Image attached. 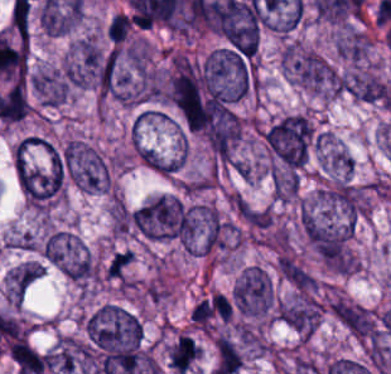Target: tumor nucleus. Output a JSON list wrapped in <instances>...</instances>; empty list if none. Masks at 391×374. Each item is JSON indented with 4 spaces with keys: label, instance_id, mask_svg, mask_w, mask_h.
Returning <instances> with one entry per match:
<instances>
[{
    "label": "tumor nucleus",
    "instance_id": "obj_1",
    "mask_svg": "<svg viewBox=\"0 0 391 374\" xmlns=\"http://www.w3.org/2000/svg\"><path fill=\"white\" fill-rule=\"evenodd\" d=\"M230 300L235 310L256 319H270L275 308V292L270 274L261 266L249 264L233 285Z\"/></svg>",
    "mask_w": 391,
    "mask_h": 374
},
{
    "label": "tumor nucleus",
    "instance_id": "obj_2",
    "mask_svg": "<svg viewBox=\"0 0 391 374\" xmlns=\"http://www.w3.org/2000/svg\"><path fill=\"white\" fill-rule=\"evenodd\" d=\"M42 258L72 281L84 282L92 276V263L85 246L62 231H54L40 244Z\"/></svg>",
    "mask_w": 391,
    "mask_h": 374
},
{
    "label": "tumor nucleus",
    "instance_id": "obj_3",
    "mask_svg": "<svg viewBox=\"0 0 391 374\" xmlns=\"http://www.w3.org/2000/svg\"><path fill=\"white\" fill-rule=\"evenodd\" d=\"M287 72L295 83L322 97L338 94L337 73L313 49L293 48L288 53Z\"/></svg>",
    "mask_w": 391,
    "mask_h": 374
},
{
    "label": "tumor nucleus",
    "instance_id": "obj_4",
    "mask_svg": "<svg viewBox=\"0 0 391 374\" xmlns=\"http://www.w3.org/2000/svg\"><path fill=\"white\" fill-rule=\"evenodd\" d=\"M63 161L71 182L86 191L107 187V167L102 155L84 141L72 139L63 146Z\"/></svg>",
    "mask_w": 391,
    "mask_h": 374
},
{
    "label": "tumor nucleus",
    "instance_id": "obj_5",
    "mask_svg": "<svg viewBox=\"0 0 391 374\" xmlns=\"http://www.w3.org/2000/svg\"><path fill=\"white\" fill-rule=\"evenodd\" d=\"M340 88L357 101L391 106V82L371 72L351 71L343 75Z\"/></svg>",
    "mask_w": 391,
    "mask_h": 374
},
{
    "label": "tumor nucleus",
    "instance_id": "obj_6",
    "mask_svg": "<svg viewBox=\"0 0 391 374\" xmlns=\"http://www.w3.org/2000/svg\"><path fill=\"white\" fill-rule=\"evenodd\" d=\"M279 318L300 337H308L319 320L315 299L303 298L279 304Z\"/></svg>",
    "mask_w": 391,
    "mask_h": 374
},
{
    "label": "tumor nucleus",
    "instance_id": "obj_7",
    "mask_svg": "<svg viewBox=\"0 0 391 374\" xmlns=\"http://www.w3.org/2000/svg\"><path fill=\"white\" fill-rule=\"evenodd\" d=\"M199 347L187 335H179L168 350L170 367L181 374H185L194 360Z\"/></svg>",
    "mask_w": 391,
    "mask_h": 374
},
{
    "label": "tumor nucleus",
    "instance_id": "obj_8",
    "mask_svg": "<svg viewBox=\"0 0 391 374\" xmlns=\"http://www.w3.org/2000/svg\"><path fill=\"white\" fill-rule=\"evenodd\" d=\"M335 46L338 55L357 62L365 55L368 40L361 32L348 28L338 35Z\"/></svg>",
    "mask_w": 391,
    "mask_h": 374
},
{
    "label": "tumor nucleus",
    "instance_id": "obj_9",
    "mask_svg": "<svg viewBox=\"0 0 391 374\" xmlns=\"http://www.w3.org/2000/svg\"><path fill=\"white\" fill-rule=\"evenodd\" d=\"M240 359L236 342L221 335L216 340L215 370L221 373H236Z\"/></svg>",
    "mask_w": 391,
    "mask_h": 374
},
{
    "label": "tumor nucleus",
    "instance_id": "obj_10",
    "mask_svg": "<svg viewBox=\"0 0 391 374\" xmlns=\"http://www.w3.org/2000/svg\"><path fill=\"white\" fill-rule=\"evenodd\" d=\"M131 263L132 254L127 249L115 251L105 263L102 275L107 280L127 284Z\"/></svg>",
    "mask_w": 391,
    "mask_h": 374
},
{
    "label": "tumor nucleus",
    "instance_id": "obj_11",
    "mask_svg": "<svg viewBox=\"0 0 391 374\" xmlns=\"http://www.w3.org/2000/svg\"><path fill=\"white\" fill-rule=\"evenodd\" d=\"M130 28L131 22L126 11H119L112 15L106 37L111 44H123L128 38Z\"/></svg>",
    "mask_w": 391,
    "mask_h": 374
}]
</instances>
